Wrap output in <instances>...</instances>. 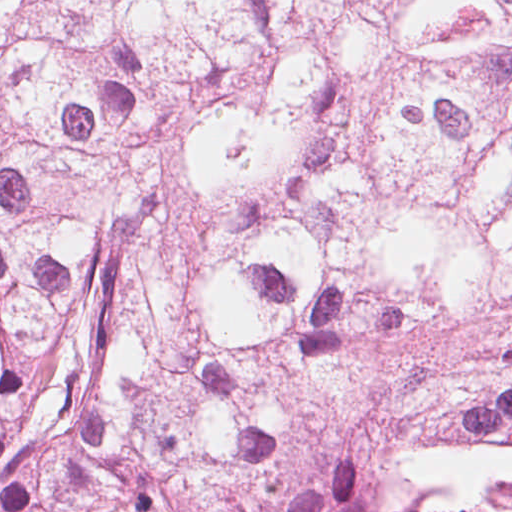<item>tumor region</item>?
Returning <instances> with one entry per match:
<instances>
[{"instance_id":"tumor-region-1","label":"tumor region","mask_w":512,"mask_h":512,"mask_svg":"<svg viewBox=\"0 0 512 512\" xmlns=\"http://www.w3.org/2000/svg\"><path fill=\"white\" fill-rule=\"evenodd\" d=\"M0 512H512V94L0 2Z\"/></svg>"}]
</instances>
